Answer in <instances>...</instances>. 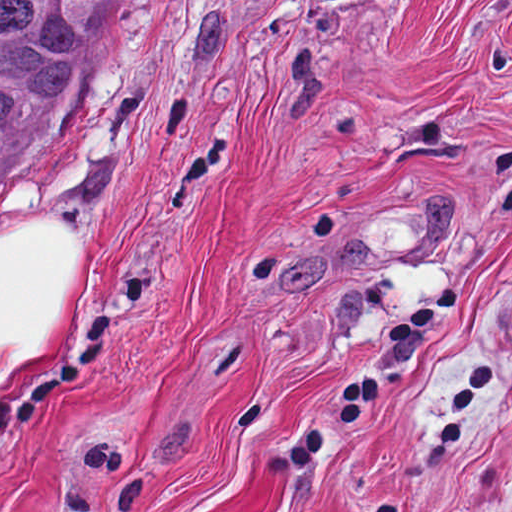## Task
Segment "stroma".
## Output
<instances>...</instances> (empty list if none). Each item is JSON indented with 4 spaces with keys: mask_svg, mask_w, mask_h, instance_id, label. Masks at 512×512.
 I'll return each mask as SVG.
<instances>
[{
    "mask_svg": "<svg viewBox=\"0 0 512 512\" xmlns=\"http://www.w3.org/2000/svg\"><path fill=\"white\" fill-rule=\"evenodd\" d=\"M89 52L0 160V237L79 235L0 512H512V0H111Z\"/></svg>",
    "mask_w": 512,
    "mask_h": 512,
    "instance_id": "obj_1",
    "label": "stroma"
}]
</instances>
